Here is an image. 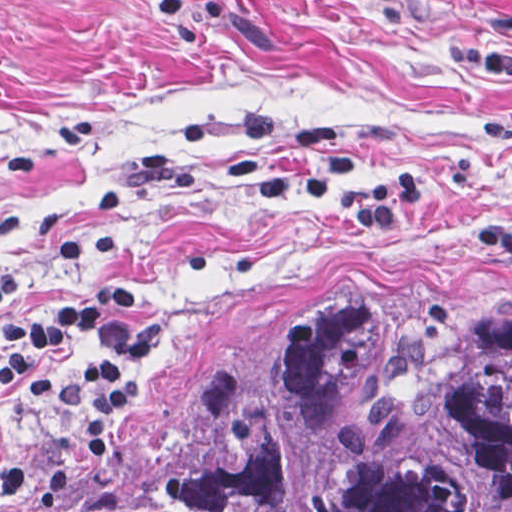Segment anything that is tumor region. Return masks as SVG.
Returning <instances> with one entry per match:
<instances>
[{
  "label": "tumor region",
  "instance_id": "1",
  "mask_svg": "<svg viewBox=\"0 0 512 512\" xmlns=\"http://www.w3.org/2000/svg\"><path fill=\"white\" fill-rule=\"evenodd\" d=\"M36 512H512V309L365 320L89 455Z\"/></svg>",
  "mask_w": 512,
  "mask_h": 512
}]
</instances>
